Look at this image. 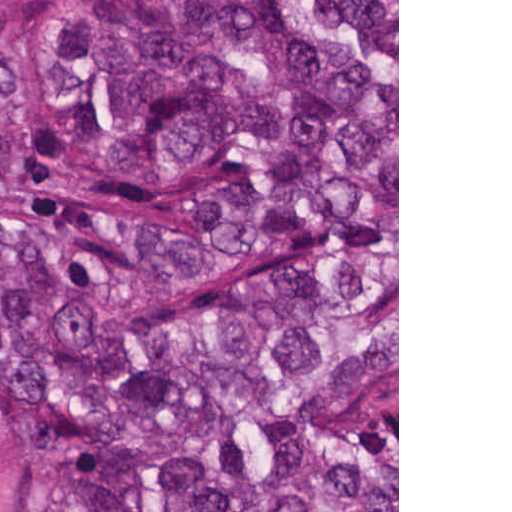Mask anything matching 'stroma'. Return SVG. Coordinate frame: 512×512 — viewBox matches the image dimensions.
I'll use <instances>...</instances> for the list:
<instances>
[{"instance_id":"35a3bbf8","label":"stroma","mask_w":512,"mask_h":512,"mask_svg":"<svg viewBox=\"0 0 512 512\" xmlns=\"http://www.w3.org/2000/svg\"><path fill=\"white\" fill-rule=\"evenodd\" d=\"M397 4V373L362 415H397L399 512V0ZM44 7H0V228L62 227L133 252L152 235L186 229L207 175L139 182L83 153L54 101ZM256 75V74H254ZM259 76V75H256ZM261 77V76H259ZM262 78V77H261ZM280 134L222 162L251 161L289 140ZM63 440L55 419L16 380L0 375V512H62Z\"/></svg>"}]
</instances>
